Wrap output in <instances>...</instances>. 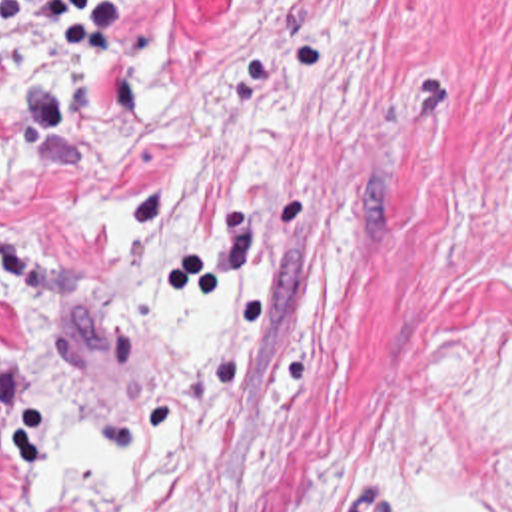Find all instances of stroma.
Wrapping results in <instances>:
<instances>
[{
  "label": "stroma",
  "instance_id": "stroma-1",
  "mask_svg": "<svg viewBox=\"0 0 512 512\" xmlns=\"http://www.w3.org/2000/svg\"><path fill=\"white\" fill-rule=\"evenodd\" d=\"M189 170L237 234V372L185 444L35 502L53 420L3 262ZM512 512V0H137L83 66L0 34V512Z\"/></svg>",
  "mask_w": 512,
  "mask_h": 512
}]
</instances>
